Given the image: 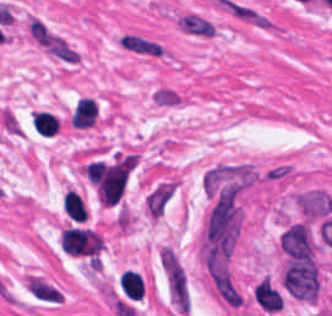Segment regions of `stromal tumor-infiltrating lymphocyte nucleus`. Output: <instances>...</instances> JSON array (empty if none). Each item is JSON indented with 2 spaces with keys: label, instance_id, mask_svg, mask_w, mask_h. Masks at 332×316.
<instances>
[{
  "label": "stromal tumor-infiltrating lymphocyte nucleus",
  "instance_id": "obj_2",
  "mask_svg": "<svg viewBox=\"0 0 332 316\" xmlns=\"http://www.w3.org/2000/svg\"><path fill=\"white\" fill-rule=\"evenodd\" d=\"M31 120L35 132L48 137L57 133L59 129L57 118L47 111H34Z\"/></svg>",
  "mask_w": 332,
  "mask_h": 316
},
{
  "label": "stromal tumor-infiltrating lymphocyte nucleus",
  "instance_id": "obj_3",
  "mask_svg": "<svg viewBox=\"0 0 332 316\" xmlns=\"http://www.w3.org/2000/svg\"><path fill=\"white\" fill-rule=\"evenodd\" d=\"M63 210L74 221H85L87 211L84 202L74 191H67L62 200Z\"/></svg>",
  "mask_w": 332,
  "mask_h": 316
},
{
  "label": "stromal tumor-infiltrating lymphocyte nucleus",
  "instance_id": "obj_1",
  "mask_svg": "<svg viewBox=\"0 0 332 316\" xmlns=\"http://www.w3.org/2000/svg\"><path fill=\"white\" fill-rule=\"evenodd\" d=\"M119 289L129 300H141L144 290L140 274L126 269L121 274Z\"/></svg>",
  "mask_w": 332,
  "mask_h": 316
}]
</instances>
